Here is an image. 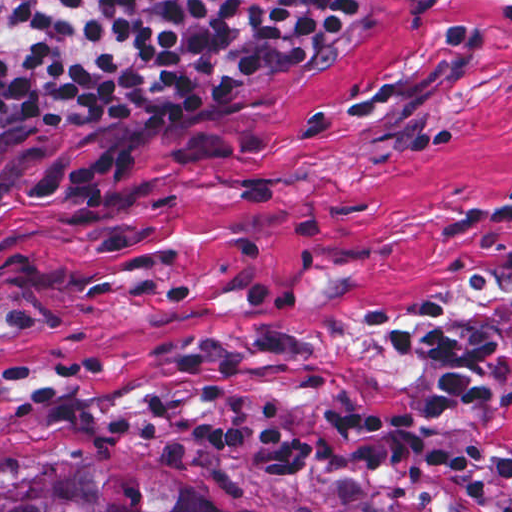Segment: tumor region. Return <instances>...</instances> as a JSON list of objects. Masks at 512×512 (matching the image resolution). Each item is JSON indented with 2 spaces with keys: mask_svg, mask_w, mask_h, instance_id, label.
Returning a JSON list of instances; mask_svg holds the SVG:
<instances>
[{
  "mask_svg": "<svg viewBox=\"0 0 512 512\" xmlns=\"http://www.w3.org/2000/svg\"><path fill=\"white\" fill-rule=\"evenodd\" d=\"M0 512H216L94 446H39L0 460Z\"/></svg>",
  "mask_w": 512,
  "mask_h": 512,
  "instance_id": "1",
  "label": "tumor region"
}]
</instances>
